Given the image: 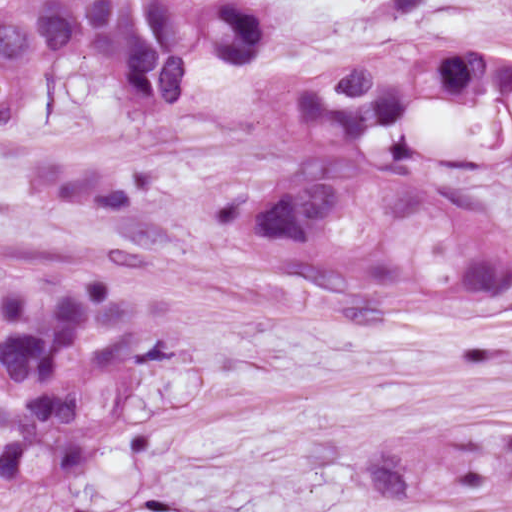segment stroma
Listing matches in <instances>:
<instances>
[{
  "instance_id": "35a3bbf8",
  "label": "stroma",
  "mask_w": 512,
  "mask_h": 512,
  "mask_svg": "<svg viewBox=\"0 0 512 512\" xmlns=\"http://www.w3.org/2000/svg\"><path fill=\"white\" fill-rule=\"evenodd\" d=\"M73 512H512V289L95 474Z\"/></svg>"
}]
</instances>
